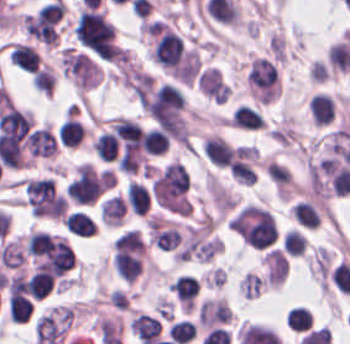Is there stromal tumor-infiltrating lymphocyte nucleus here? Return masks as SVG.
Masks as SVG:
<instances>
[{"instance_id": "bc302bb0", "label": "stromal tumor-infiltrating lymphocyte nucleus", "mask_w": 350, "mask_h": 344, "mask_svg": "<svg viewBox=\"0 0 350 344\" xmlns=\"http://www.w3.org/2000/svg\"><path fill=\"white\" fill-rule=\"evenodd\" d=\"M202 153L216 165L229 166L233 153L226 141L217 133L202 137Z\"/></svg>"}, {"instance_id": "52c7bb5b", "label": "stromal tumor-infiltrating lymphocyte nucleus", "mask_w": 350, "mask_h": 344, "mask_svg": "<svg viewBox=\"0 0 350 344\" xmlns=\"http://www.w3.org/2000/svg\"><path fill=\"white\" fill-rule=\"evenodd\" d=\"M26 147L31 156L49 157L57 148L49 127L33 130L26 138Z\"/></svg>"}, {"instance_id": "3290ff9b", "label": "stromal tumor-infiltrating lymphocyte nucleus", "mask_w": 350, "mask_h": 344, "mask_svg": "<svg viewBox=\"0 0 350 344\" xmlns=\"http://www.w3.org/2000/svg\"><path fill=\"white\" fill-rule=\"evenodd\" d=\"M228 123L239 129H259L266 122L258 110L247 103H239L233 110Z\"/></svg>"}, {"instance_id": "abfb95fc", "label": "stromal tumor-infiltrating lymphocyte nucleus", "mask_w": 350, "mask_h": 344, "mask_svg": "<svg viewBox=\"0 0 350 344\" xmlns=\"http://www.w3.org/2000/svg\"><path fill=\"white\" fill-rule=\"evenodd\" d=\"M87 129L70 113L59 126L58 139L66 148H77L84 139Z\"/></svg>"}, {"instance_id": "9ea309e8", "label": "stromal tumor-infiltrating lymphocyte nucleus", "mask_w": 350, "mask_h": 344, "mask_svg": "<svg viewBox=\"0 0 350 344\" xmlns=\"http://www.w3.org/2000/svg\"><path fill=\"white\" fill-rule=\"evenodd\" d=\"M335 103L325 91H317L310 97V114L315 124L325 126L333 117Z\"/></svg>"}, {"instance_id": "f3e2335f", "label": "stromal tumor-infiltrating lymphocyte nucleus", "mask_w": 350, "mask_h": 344, "mask_svg": "<svg viewBox=\"0 0 350 344\" xmlns=\"http://www.w3.org/2000/svg\"><path fill=\"white\" fill-rule=\"evenodd\" d=\"M161 323L150 314L136 313L129 322L130 333L141 342L154 339L159 334Z\"/></svg>"}, {"instance_id": "4f13568d", "label": "stromal tumor-infiltrating lymphocyte nucleus", "mask_w": 350, "mask_h": 344, "mask_svg": "<svg viewBox=\"0 0 350 344\" xmlns=\"http://www.w3.org/2000/svg\"><path fill=\"white\" fill-rule=\"evenodd\" d=\"M126 207L119 195H112L99 204V221L104 226L116 227L122 220Z\"/></svg>"}, {"instance_id": "2a367800", "label": "stromal tumor-infiltrating lymphocyte nucleus", "mask_w": 350, "mask_h": 344, "mask_svg": "<svg viewBox=\"0 0 350 344\" xmlns=\"http://www.w3.org/2000/svg\"><path fill=\"white\" fill-rule=\"evenodd\" d=\"M124 201L136 216H144L149 210L150 198L139 182L129 181L125 188Z\"/></svg>"}, {"instance_id": "4803ca6d", "label": "stromal tumor-infiltrating lymphocyte nucleus", "mask_w": 350, "mask_h": 344, "mask_svg": "<svg viewBox=\"0 0 350 344\" xmlns=\"http://www.w3.org/2000/svg\"><path fill=\"white\" fill-rule=\"evenodd\" d=\"M9 57L12 65L22 71H36L38 68L37 53L31 45L11 43Z\"/></svg>"}, {"instance_id": "4245b91a", "label": "stromal tumor-infiltrating lymphocyte nucleus", "mask_w": 350, "mask_h": 344, "mask_svg": "<svg viewBox=\"0 0 350 344\" xmlns=\"http://www.w3.org/2000/svg\"><path fill=\"white\" fill-rule=\"evenodd\" d=\"M62 222L69 232L77 237H90L97 228L94 220L82 210L72 211Z\"/></svg>"}, {"instance_id": "4c9ddf68", "label": "stromal tumor-infiltrating lymphocyte nucleus", "mask_w": 350, "mask_h": 344, "mask_svg": "<svg viewBox=\"0 0 350 344\" xmlns=\"http://www.w3.org/2000/svg\"><path fill=\"white\" fill-rule=\"evenodd\" d=\"M198 286V282L187 275H180L172 282V290L184 310H192Z\"/></svg>"}, {"instance_id": "2761f720", "label": "stromal tumor-infiltrating lymphocyte nucleus", "mask_w": 350, "mask_h": 344, "mask_svg": "<svg viewBox=\"0 0 350 344\" xmlns=\"http://www.w3.org/2000/svg\"><path fill=\"white\" fill-rule=\"evenodd\" d=\"M291 213L300 226L313 230L320 226L321 215L311 201H298L291 209Z\"/></svg>"}, {"instance_id": "3c572f05", "label": "stromal tumor-infiltrating lymphocyte nucleus", "mask_w": 350, "mask_h": 344, "mask_svg": "<svg viewBox=\"0 0 350 344\" xmlns=\"http://www.w3.org/2000/svg\"><path fill=\"white\" fill-rule=\"evenodd\" d=\"M142 145L148 155H162L170 147V141L159 127H151L143 133Z\"/></svg>"}, {"instance_id": "42bb06b2", "label": "stromal tumor-infiltrating lymphocyte nucleus", "mask_w": 350, "mask_h": 344, "mask_svg": "<svg viewBox=\"0 0 350 344\" xmlns=\"http://www.w3.org/2000/svg\"><path fill=\"white\" fill-rule=\"evenodd\" d=\"M285 323L289 329L305 331L312 325L310 310L300 307H290L285 315Z\"/></svg>"}, {"instance_id": "9e4306bb", "label": "stromal tumor-infiltrating lymphocyte nucleus", "mask_w": 350, "mask_h": 344, "mask_svg": "<svg viewBox=\"0 0 350 344\" xmlns=\"http://www.w3.org/2000/svg\"><path fill=\"white\" fill-rule=\"evenodd\" d=\"M167 333L172 340L178 342L179 344L190 342L196 336V332L192 324L183 319L171 324Z\"/></svg>"}, {"instance_id": "04cf8593", "label": "stromal tumor-infiltrating lymphocyte nucleus", "mask_w": 350, "mask_h": 344, "mask_svg": "<svg viewBox=\"0 0 350 344\" xmlns=\"http://www.w3.org/2000/svg\"><path fill=\"white\" fill-rule=\"evenodd\" d=\"M34 87L51 97L54 87V72L48 65L45 64L35 72Z\"/></svg>"}, {"instance_id": "e9af9c67", "label": "stromal tumor-infiltrating lymphocyte nucleus", "mask_w": 350, "mask_h": 344, "mask_svg": "<svg viewBox=\"0 0 350 344\" xmlns=\"http://www.w3.org/2000/svg\"><path fill=\"white\" fill-rule=\"evenodd\" d=\"M304 250V237L295 230H288L283 236V252L290 256H301Z\"/></svg>"}, {"instance_id": "782c7336", "label": "stromal tumor-infiltrating lymphocyte nucleus", "mask_w": 350, "mask_h": 344, "mask_svg": "<svg viewBox=\"0 0 350 344\" xmlns=\"http://www.w3.org/2000/svg\"><path fill=\"white\" fill-rule=\"evenodd\" d=\"M239 286L246 298H255L263 289V282L254 272H247L241 279Z\"/></svg>"}]
</instances>
